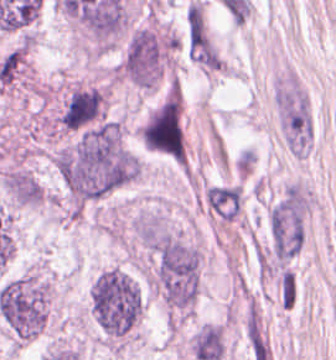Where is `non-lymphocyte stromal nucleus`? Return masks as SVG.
Wrapping results in <instances>:
<instances>
[{"label":"non-lymphocyte stromal nucleus","instance_id":"a72fc3eb","mask_svg":"<svg viewBox=\"0 0 336 360\" xmlns=\"http://www.w3.org/2000/svg\"><path fill=\"white\" fill-rule=\"evenodd\" d=\"M279 304L288 309L294 301L293 273L288 269H281L277 275Z\"/></svg>","mask_w":336,"mask_h":360},{"label":"non-lymphocyte stromal nucleus","instance_id":"dd21d789","mask_svg":"<svg viewBox=\"0 0 336 360\" xmlns=\"http://www.w3.org/2000/svg\"><path fill=\"white\" fill-rule=\"evenodd\" d=\"M184 49L189 59L200 67L212 71L220 68L221 57L198 1L191 0L186 6Z\"/></svg>","mask_w":336,"mask_h":360}]
</instances>
